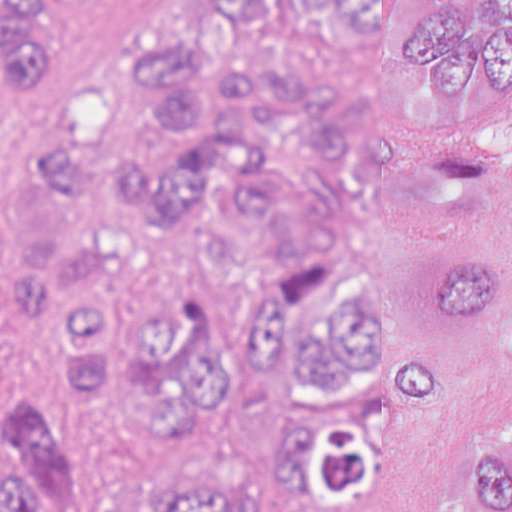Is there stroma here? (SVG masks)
Instances as JSON below:
<instances>
[{"label":"stroma","mask_w":512,"mask_h":512,"mask_svg":"<svg viewBox=\"0 0 512 512\" xmlns=\"http://www.w3.org/2000/svg\"><path fill=\"white\" fill-rule=\"evenodd\" d=\"M6 0H0V5ZM203 0H43L31 42L43 73L22 94L0 80V208L40 178V135L72 89H113V48L164 11ZM487 439L512 444V338L456 336L444 400L424 408L420 432L379 445L372 490L381 512H438L463 496L471 451Z\"/></svg>","instance_id":"35a3bbf8"}]
</instances>
